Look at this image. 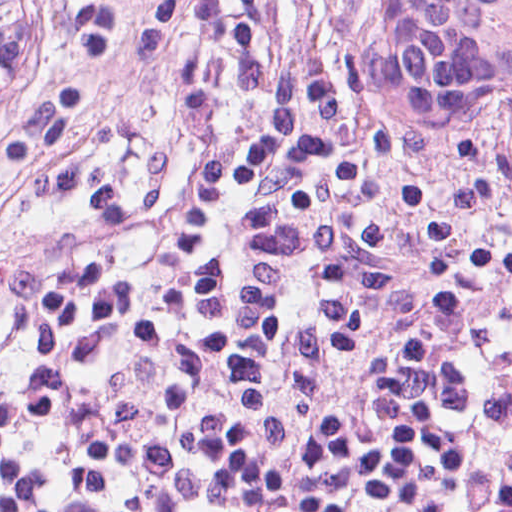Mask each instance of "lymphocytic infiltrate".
Listing matches in <instances>:
<instances>
[{"mask_svg": "<svg viewBox=\"0 0 512 512\" xmlns=\"http://www.w3.org/2000/svg\"><path fill=\"white\" fill-rule=\"evenodd\" d=\"M370 0H257L255 114L243 139L171 203L85 224L32 254L0 303L117 260L160 235L230 164L312 163L385 177L512 215V147L444 125L391 95L365 54ZM35 224L0 198V242Z\"/></svg>", "mask_w": 512, "mask_h": 512, "instance_id": "obj_1", "label": "lymphocytic infiltrate"}]
</instances>
